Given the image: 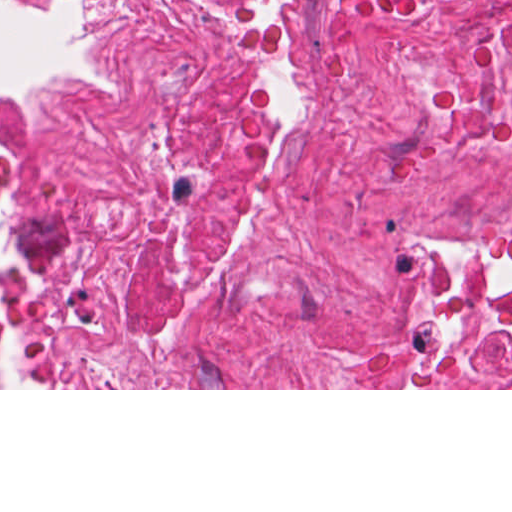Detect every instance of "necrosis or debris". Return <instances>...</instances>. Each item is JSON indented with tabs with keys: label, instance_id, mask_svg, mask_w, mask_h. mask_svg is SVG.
Instances as JSON below:
<instances>
[{
	"label": "necrosis or debris",
	"instance_id": "1",
	"mask_svg": "<svg viewBox=\"0 0 512 512\" xmlns=\"http://www.w3.org/2000/svg\"><path fill=\"white\" fill-rule=\"evenodd\" d=\"M512 386V0H93L0 106V388Z\"/></svg>",
	"mask_w": 512,
	"mask_h": 512
}]
</instances>
